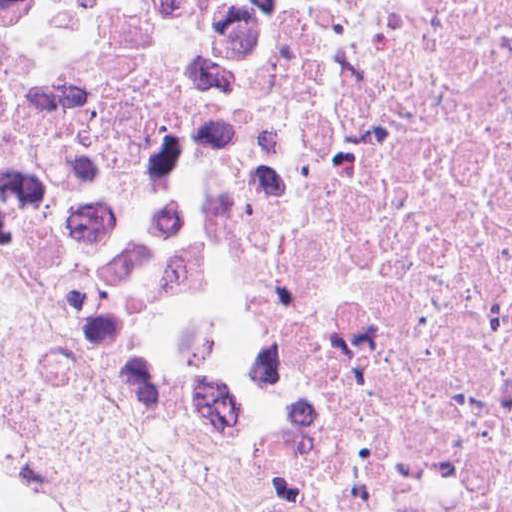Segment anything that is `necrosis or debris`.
Segmentation results:
<instances>
[{
    "instance_id": "1",
    "label": "necrosis or debris",
    "mask_w": 512,
    "mask_h": 512,
    "mask_svg": "<svg viewBox=\"0 0 512 512\" xmlns=\"http://www.w3.org/2000/svg\"><path fill=\"white\" fill-rule=\"evenodd\" d=\"M0 292L345 512H512V0H0ZM0 512H83L0 438Z\"/></svg>"
}]
</instances>
